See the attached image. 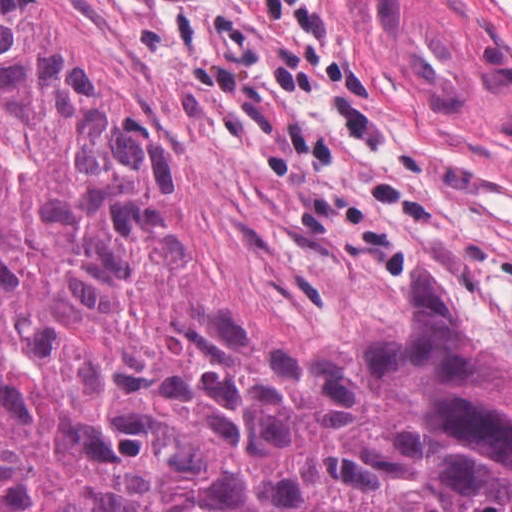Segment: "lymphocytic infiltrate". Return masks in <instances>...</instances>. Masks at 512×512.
Returning a JSON list of instances; mask_svg holds the SVG:
<instances>
[{"instance_id":"obj_1","label":"lymphocytic infiltrate","mask_w":512,"mask_h":512,"mask_svg":"<svg viewBox=\"0 0 512 512\" xmlns=\"http://www.w3.org/2000/svg\"><path fill=\"white\" fill-rule=\"evenodd\" d=\"M94 1L160 98L273 177L319 245L412 257L405 220H427L437 205L419 187L379 191L298 118L321 113L355 140L394 145L345 50L334 0Z\"/></svg>"}]
</instances>
